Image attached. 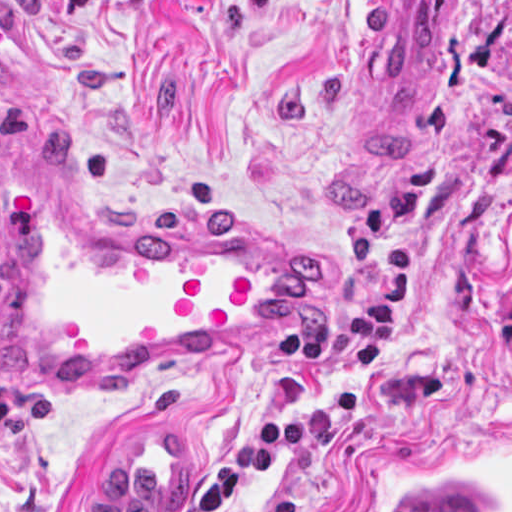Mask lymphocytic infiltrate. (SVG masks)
<instances>
[{"mask_svg":"<svg viewBox=\"0 0 512 512\" xmlns=\"http://www.w3.org/2000/svg\"><path fill=\"white\" fill-rule=\"evenodd\" d=\"M311 445V421L297 412H276L243 433L224 455L201 493L202 512H239L254 479L272 472L274 458ZM0 512H7L0 506Z\"/></svg>","mask_w":512,"mask_h":512,"instance_id":"obj_1","label":"lymphocytic infiltrate"}]
</instances>
